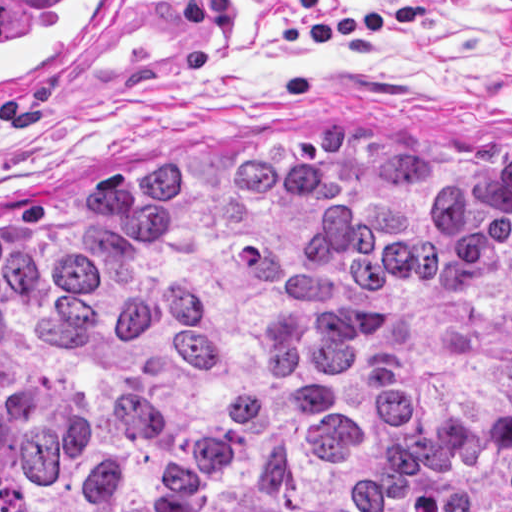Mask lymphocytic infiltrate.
Returning <instances> with one entry per match:
<instances>
[{"instance_id":"obj_1","label":"lymphocytic infiltrate","mask_w":512,"mask_h":512,"mask_svg":"<svg viewBox=\"0 0 512 512\" xmlns=\"http://www.w3.org/2000/svg\"><path fill=\"white\" fill-rule=\"evenodd\" d=\"M289 8H310L322 0H286ZM512 4V0H505ZM235 7L229 0H186L182 18L187 25L202 21L219 28L230 26ZM429 18L423 0H399L384 9H369L320 22H278L271 25V37L281 49H302L334 44L351 60H361L374 47L379 33H391L423 23Z\"/></svg>"}]
</instances>
